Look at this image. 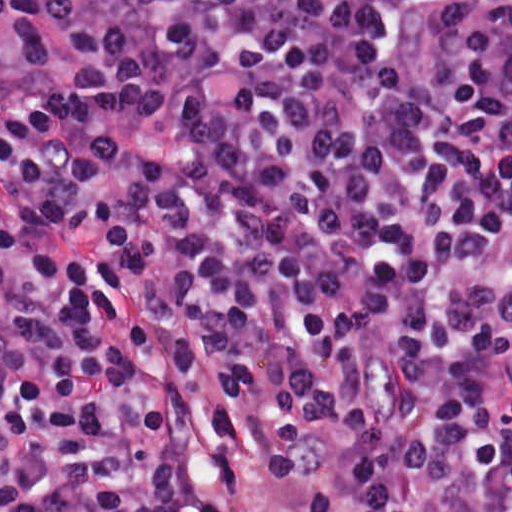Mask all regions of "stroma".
Returning <instances> with one entry per match:
<instances>
[{"label":"stroma","mask_w":512,"mask_h":512,"mask_svg":"<svg viewBox=\"0 0 512 512\" xmlns=\"http://www.w3.org/2000/svg\"><path fill=\"white\" fill-rule=\"evenodd\" d=\"M12 1L13 0H0V53H3L8 49L11 38ZM475 267L503 318L512 326V316L499 302L492 290V273L495 266L475 265Z\"/></svg>","instance_id":"1"}]
</instances>
